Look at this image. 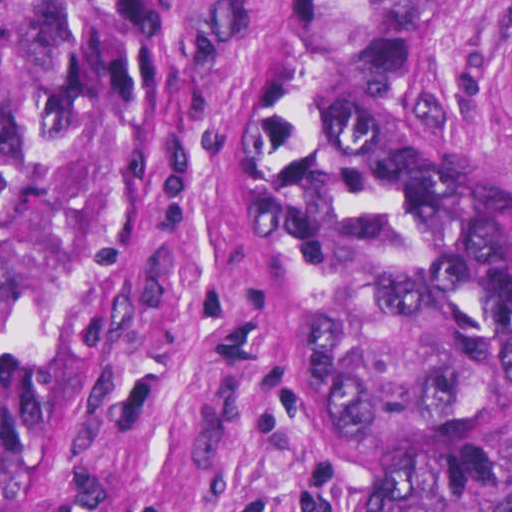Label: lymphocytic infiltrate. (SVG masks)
Here are the masks:
<instances>
[{
    "label": "lymphocytic infiltrate",
    "mask_w": 512,
    "mask_h": 512,
    "mask_svg": "<svg viewBox=\"0 0 512 512\" xmlns=\"http://www.w3.org/2000/svg\"><path fill=\"white\" fill-rule=\"evenodd\" d=\"M270 480L262 486L246 492L222 507L219 512H268V488ZM300 512H337L317 492Z\"/></svg>",
    "instance_id": "1"
}]
</instances>
